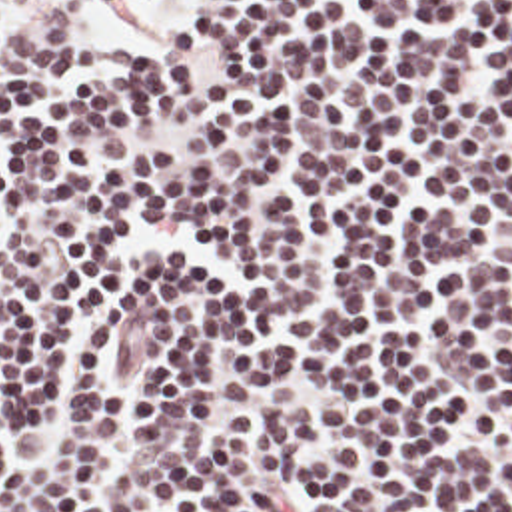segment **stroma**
Returning a JSON list of instances; mask_svg holds the SVG:
<instances>
[{
	"label": "stroma",
	"mask_w": 512,
	"mask_h": 512,
	"mask_svg": "<svg viewBox=\"0 0 512 512\" xmlns=\"http://www.w3.org/2000/svg\"><path fill=\"white\" fill-rule=\"evenodd\" d=\"M0 6L13 12L23 24L57 34H77L87 16L85 0H45L37 4H29L27 0H0ZM199 12L201 0H161L157 8L121 20L105 34H145L149 30L191 18Z\"/></svg>",
	"instance_id": "1"
}]
</instances>
